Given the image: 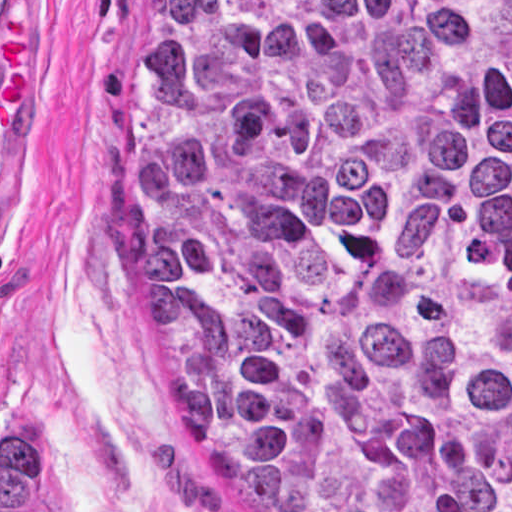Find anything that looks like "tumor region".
<instances>
[{"mask_svg":"<svg viewBox=\"0 0 512 512\" xmlns=\"http://www.w3.org/2000/svg\"><path fill=\"white\" fill-rule=\"evenodd\" d=\"M144 355L265 512H512V0H131ZM23 424L1 512H35Z\"/></svg>","mask_w":512,"mask_h":512,"instance_id":"tumor-region-1","label":"tumor region"}]
</instances>
